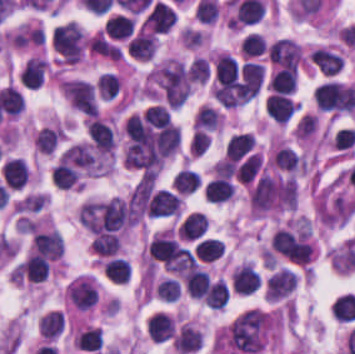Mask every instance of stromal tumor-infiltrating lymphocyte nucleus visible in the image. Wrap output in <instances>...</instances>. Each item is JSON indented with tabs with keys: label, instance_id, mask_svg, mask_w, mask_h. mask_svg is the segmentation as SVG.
Listing matches in <instances>:
<instances>
[{
	"label": "stromal tumor-infiltrating lymphocyte nucleus",
	"instance_id": "obj_25",
	"mask_svg": "<svg viewBox=\"0 0 355 354\" xmlns=\"http://www.w3.org/2000/svg\"><path fill=\"white\" fill-rule=\"evenodd\" d=\"M93 250L98 254L112 255L119 244L117 234L109 232L98 233L91 242Z\"/></svg>",
	"mask_w": 355,
	"mask_h": 354
},
{
	"label": "stromal tumor-infiltrating lymphocyte nucleus",
	"instance_id": "obj_9",
	"mask_svg": "<svg viewBox=\"0 0 355 354\" xmlns=\"http://www.w3.org/2000/svg\"><path fill=\"white\" fill-rule=\"evenodd\" d=\"M232 285L241 294H251L261 286L260 273L250 263H242L232 277Z\"/></svg>",
	"mask_w": 355,
	"mask_h": 354
},
{
	"label": "stromal tumor-infiltrating lymphocyte nucleus",
	"instance_id": "obj_17",
	"mask_svg": "<svg viewBox=\"0 0 355 354\" xmlns=\"http://www.w3.org/2000/svg\"><path fill=\"white\" fill-rule=\"evenodd\" d=\"M301 161L299 153L293 146L280 145L274 154V165L282 171H293Z\"/></svg>",
	"mask_w": 355,
	"mask_h": 354
},
{
	"label": "stromal tumor-infiltrating lymphocyte nucleus",
	"instance_id": "obj_11",
	"mask_svg": "<svg viewBox=\"0 0 355 354\" xmlns=\"http://www.w3.org/2000/svg\"><path fill=\"white\" fill-rule=\"evenodd\" d=\"M46 69L47 64L43 59L31 56L21 67L19 81L28 88H35L42 83Z\"/></svg>",
	"mask_w": 355,
	"mask_h": 354
},
{
	"label": "stromal tumor-infiltrating lymphocyte nucleus",
	"instance_id": "obj_20",
	"mask_svg": "<svg viewBox=\"0 0 355 354\" xmlns=\"http://www.w3.org/2000/svg\"><path fill=\"white\" fill-rule=\"evenodd\" d=\"M103 270L113 281L126 283L131 274V265L127 258L111 257Z\"/></svg>",
	"mask_w": 355,
	"mask_h": 354
},
{
	"label": "stromal tumor-infiltrating lymphocyte nucleus",
	"instance_id": "obj_6",
	"mask_svg": "<svg viewBox=\"0 0 355 354\" xmlns=\"http://www.w3.org/2000/svg\"><path fill=\"white\" fill-rule=\"evenodd\" d=\"M174 9L163 1H156L148 12V26L157 32H167L176 22Z\"/></svg>",
	"mask_w": 355,
	"mask_h": 354
},
{
	"label": "stromal tumor-infiltrating lymphocyte nucleus",
	"instance_id": "obj_2",
	"mask_svg": "<svg viewBox=\"0 0 355 354\" xmlns=\"http://www.w3.org/2000/svg\"><path fill=\"white\" fill-rule=\"evenodd\" d=\"M210 222L203 210H190L177 222V236L181 240L196 242L206 237Z\"/></svg>",
	"mask_w": 355,
	"mask_h": 354
},
{
	"label": "stromal tumor-infiltrating lymphocyte nucleus",
	"instance_id": "obj_1",
	"mask_svg": "<svg viewBox=\"0 0 355 354\" xmlns=\"http://www.w3.org/2000/svg\"><path fill=\"white\" fill-rule=\"evenodd\" d=\"M51 44L61 60L76 62L87 46V39L77 23L66 20L56 25Z\"/></svg>",
	"mask_w": 355,
	"mask_h": 354
},
{
	"label": "stromal tumor-infiltrating lymphocyte nucleus",
	"instance_id": "obj_16",
	"mask_svg": "<svg viewBox=\"0 0 355 354\" xmlns=\"http://www.w3.org/2000/svg\"><path fill=\"white\" fill-rule=\"evenodd\" d=\"M234 186L225 176H217L210 181L205 189L207 199L212 202H222L232 195Z\"/></svg>",
	"mask_w": 355,
	"mask_h": 354
},
{
	"label": "stromal tumor-infiltrating lymphocyte nucleus",
	"instance_id": "obj_12",
	"mask_svg": "<svg viewBox=\"0 0 355 354\" xmlns=\"http://www.w3.org/2000/svg\"><path fill=\"white\" fill-rule=\"evenodd\" d=\"M267 111L274 120L287 121L296 108V101L283 94L272 93L266 100Z\"/></svg>",
	"mask_w": 355,
	"mask_h": 354
},
{
	"label": "stromal tumor-infiltrating lymphocyte nucleus",
	"instance_id": "obj_15",
	"mask_svg": "<svg viewBox=\"0 0 355 354\" xmlns=\"http://www.w3.org/2000/svg\"><path fill=\"white\" fill-rule=\"evenodd\" d=\"M250 131H242L232 134L226 145V152L230 160H237L246 153L254 142Z\"/></svg>",
	"mask_w": 355,
	"mask_h": 354
},
{
	"label": "stromal tumor-infiltrating lymphocyte nucleus",
	"instance_id": "obj_27",
	"mask_svg": "<svg viewBox=\"0 0 355 354\" xmlns=\"http://www.w3.org/2000/svg\"><path fill=\"white\" fill-rule=\"evenodd\" d=\"M266 50L265 37L257 32H250L244 39V52L246 56L260 55Z\"/></svg>",
	"mask_w": 355,
	"mask_h": 354
},
{
	"label": "stromal tumor-infiltrating lymphocyte nucleus",
	"instance_id": "obj_14",
	"mask_svg": "<svg viewBox=\"0 0 355 354\" xmlns=\"http://www.w3.org/2000/svg\"><path fill=\"white\" fill-rule=\"evenodd\" d=\"M154 48L153 32H139L128 40L127 51L132 57L149 58Z\"/></svg>",
	"mask_w": 355,
	"mask_h": 354
},
{
	"label": "stromal tumor-infiltrating lymphocyte nucleus",
	"instance_id": "obj_19",
	"mask_svg": "<svg viewBox=\"0 0 355 354\" xmlns=\"http://www.w3.org/2000/svg\"><path fill=\"white\" fill-rule=\"evenodd\" d=\"M49 264L44 255L32 253L24 262L22 270L29 280L42 281Z\"/></svg>",
	"mask_w": 355,
	"mask_h": 354
},
{
	"label": "stromal tumor-infiltrating lymphocyte nucleus",
	"instance_id": "obj_13",
	"mask_svg": "<svg viewBox=\"0 0 355 354\" xmlns=\"http://www.w3.org/2000/svg\"><path fill=\"white\" fill-rule=\"evenodd\" d=\"M94 89L103 100H114L121 91V81L116 72H102L98 75Z\"/></svg>",
	"mask_w": 355,
	"mask_h": 354
},
{
	"label": "stromal tumor-infiltrating lymphocyte nucleus",
	"instance_id": "obj_8",
	"mask_svg": "<svg viewBox=\"0 0 355 354\" xmlns=\"http://www.w3.org/2000/svg\"><path fill=\"white\" fill-rule=\"evenodd\" d=\"M87 131L90 135L92 142L101 151L107 152L113 149V129L101 118H99L98 116H91L87 124Z\"/></svg>",
	"mask_w": 355,
	"mask_h": 354
},
{
	"label": "stromal tumor-infiltrating lymphocyte nucleus",
	"instance_id": "obj_4",
	"mask_svg": "<svg viewBox=\"0 0 355 354\" xmlns=\"http://www.w3.org/2000/svg\"><path fill=\"white\" fill-rule=\"evenodd\" d=\"M179 198L176 193L166 189L153 191L147 204L148 216H167L176 214Z\"/></svg>",
	"mask_w": 355,
	"mask_h": 354
},
{
	"label": "stromal tumor-infiltrating lymphocyte nucleus",
	"instance_id": "obj_23",
	"mask_svg": "<svg viewBox=\"0 0 355 354\" xmlns=\"http://www.w3.org/2000/svg\"><path fill=\"white\" fill-rule=\"evenodd\" d=\"M133 19L131 16L115 14L103 25L107 35L110 37H123L132 29Z\"/></svg>",
	"mask_w": 355,
	"mask_h": 354
},
{
	"label": "stromal tumor-infiltrating lymphocyte nucleus",
	"instance_id": "obj_24",
	"mask_svg": "<svg viewBox=\"0 0 355 354\" xmlns=\"http://www.w3.org/2000/svg\"><path fill=\"white\" fill-rule=\"evenodd\" d=\"M76 342L80 349L99 350L103 344L102 328H88L77 335Z\"/></svg>",
	"mask_w": 355,
	"mask_h": 354
},
{
	"label": "stromal tumor-infiltrating lymphocyte nucleus",
	"instance_id": "obj_5",
	"mask_svg": "<svg viewBox=\"0 0 355 354\" xmlns=\"http://www.w3.org/2000/svg\"><path fill=\"white\" fill-rule=\"evenodd\" d=\"M311 62L324 75L335 76L344 64V57L338 51L326 46H319L314 50Z\"/></svg>",
	"mask_w": 355,
	"mask_h": 354
},
{
	"label": "stromal tumor-infiltrating lymphocyte nucleus",
	"instance_id": "obj_28",
	"mask_svg": "<svg viewBox=\"0 0 355 354\" xmlns=\"http://www.w3.org/2000/svg\"><path fill=\"white\" fill-rule=\"evenodd\" d=\"M217 111L210 105H202L196 114V127H217Z\"/></svg>",
	"mask_w": 355,
	"mask_h": 354
},
{
	"label": "stromal tumor-infiltrating lymphocyte nucleus",
	"instance_id": "obj_18",
	"mask_svg": "<svg viewBox=\"0 0 355 354\" xmlns=\"http://www.w3.org/2000/svg\"><path fill=\"white\" fill-rule=\"evenodd\" d=\"M183 354L198 349L202 338L192 325H184L173 343Z\"/></svg>",
	"mask_w": 355,
	"mask_h": 354
},
{
	"label": "stromal tumor-infiltrating lymphocyte nucleus",
	"instance_id": "obj_10",
	"mask_svg": "<svg viewBox=\"0 0 355 354\" xmlns=\"http://www.w3.org/2000/svg\"><path fill=\"white\" fill-rule=\"evenodd\" d=\"M296 286V277L292 270L280 269L267 279V295L278 299L287 295Z\"/></svg>",
	"mask_w": 355,
	"mask_h": 354
},
{
	"label": "stromal tumor-infiltrating lymphocyte nucleus",
	"instance_id": "obj_3",
	"mask_svg": "<svg viewBox=\"0 0 355 354\" xmlns=\"http://www.w3.org/2000/svg\"><path fill=\"white\" fill-rule=\"evenodd\" d=\"M146 333L150 339L165 342L174 336V319L162 310H155L146 318Z\"/></svg>",
	"mask_w": 355,
	"mask_h": 354
},
{
	"label": "stromal tumor-infiltrating lymphocyte nucleus",
	"instance_id": "obj_7",
	"mask_svg": "<svg viewBox=\"0 0 355 354\" xmlns=\"http://www.w3.org/2000/svg\"><path fill=\"white\" fill-rule=\"evenodd\" d=\"M33 247L34 250L54 259L62 255L63 241L55 229L38 231L33 237Z\"/></svg>",
	"mask_w": 355,
	"mask_h": 354
},
{
	"label": "stromal tumor-infiltrating lymphocyte nucleus",
	"instance_id": "obj_21",
	"mask_svg": "<svg viewBox=\"0 0 355 354\" xmlns=\"http://www.w3.org/2000/svg\"><path fill=\"white\" fill-rule=\"evenodd\" d=\"M272 91L291 92L296 87V71L279 68L269 80Z\"/></svg>",
	"mask_w": 355,
	"mask_h": 354
},
{
	"label": "stromal tumor-infiltrating lymphocyte nucleus",
	"instance_id": "obj_22",
	"mask_svg": "<svg viewBox=\"0 0 355 354\" xmlns=\"http://www.w3.org/2000/svg\"><path fill=\"white\" fill-rule=\"evenodd\" d=\"M196 255L202 260H216L223 253L221 239L205 237L195 245Z\"/></svg>",
	"mask_w": 355,
	"mask_h": 354
},
{
	"label": "stromal tumor-infiltrating lymphocyte nucleus",
	"instance_id": "obj_26",
	"mask_svg": "<svg viewBox=\"0 0 355 354\" xmlns=\"http://www.w3.org/2000/svg\"><path fill=\"white\" fill-rule=\"evenodd\" d=\"M173 180L183 192H192L201 182L198 171L189 168L179 170Z\"/></svg>",
	"mask_w": 355,
	"mask_h": 354
}]
</instances>
